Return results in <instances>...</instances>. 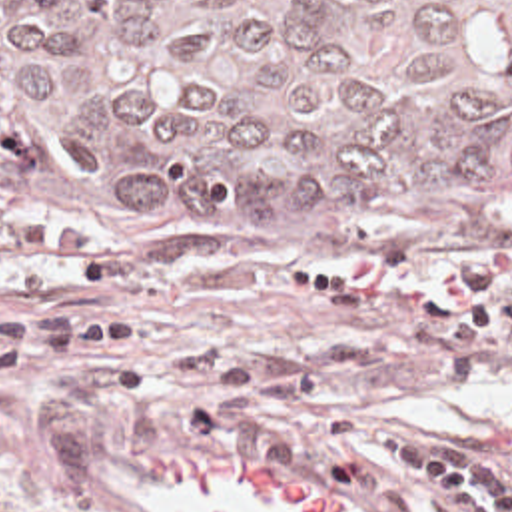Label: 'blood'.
I'll list each match as a JSON object with an SVG mask.
<instances>
[{
    "label": "blood",
    "mask_w": 512,
    "mask_h": 512,
    "mask_svg": "<svg viewBox=\"0 0 512 512\" xmlns=\"http://www.w3.org/2000/svg\"><path fill=\"white\" fill-rule=\"evenodd\" d=\"M480 456H512V416L478 426ZM153 494L175 512H352L350 504L307 480L255 468L233 456H173L151 464Z\"/></svg>",
    "instance_id": "obj_1"
}]
</instances>
